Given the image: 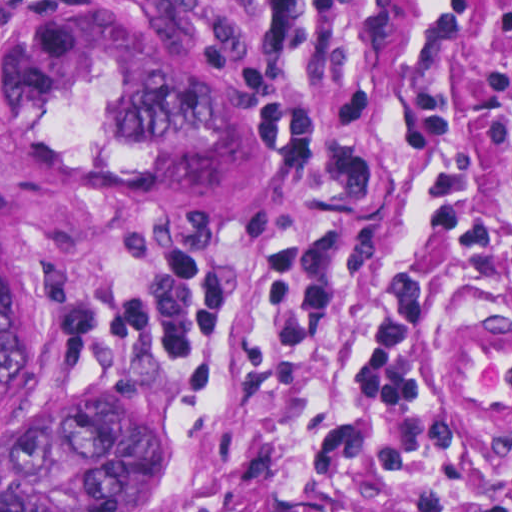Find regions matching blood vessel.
I'll use <instances>...</instances> for the list:
<instances>
[{
  "label": "blood vessel",
  "instance_id": "8fb6f2fc",
  "mask_svg": "<svg viewBox=\"0 0 512 512\" xmlns=\"http://www.w3.org/2000/svg\"><path fill=\"white\" fill-rule=\"evenodd\" d=\"M434 371L456 399L512 398V335L480 333L436 345Z\"/></svg>",
  "mask_w": 512,
  "mask_h": 512
}]
</instances>
